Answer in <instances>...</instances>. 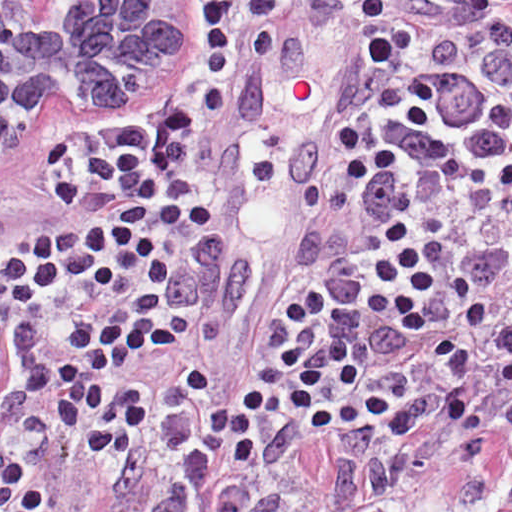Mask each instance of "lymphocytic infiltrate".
I'll return each instance as SVG.
<instances>
[{
    "instance_id": "1",
    "label": "lymphocytic infiltrate",
    "mask_w": 512,
    "mask_h": 512,
    "mask_svg": "<svg viewBox=\"0 0 512 512\" xmlns=\"http://www.w3.org/2000/svg\"><path fill=\"white\" fill-rule=\"evenodd\" d=\"M173 241V201L156 156L130 139L88 162L78 188L56 210L52 233L28 252L0 244V512H58L35 474L13 454V379L34 354L62 307H93L141 283ZM438 246L424 253L411 231L391 221L382 251L370 263L378 291L366 303L415 336L431 323L423 302L438 292ZM161 302L136 291L103 315H80L59 332L63 355L21 374L24 392L45 397L48 414L80 447L120 457L143 434L146 400L134 386L108 393L107 376L137 355L174 344L156 318ZM277 356L289 381L251 380L223 396L201 427L204 450L227 453L235 465L258 457V431L287 416L314 433L370 421L366 394L388 395L361 374L357 353L329 336L317 357L306 355L300 330L306 308L291 299Z\"/></svg>"
}]
</instances>
